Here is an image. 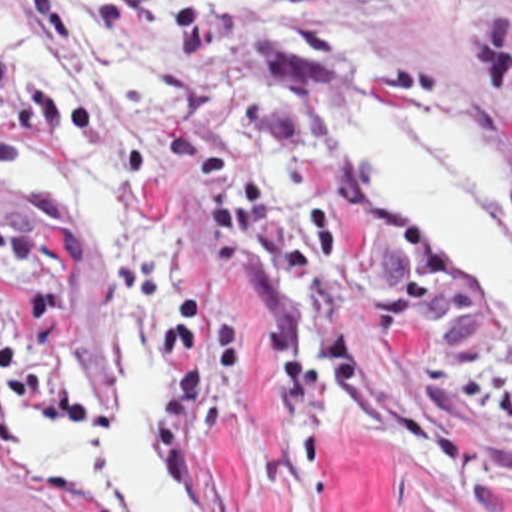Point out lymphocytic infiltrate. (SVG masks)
Segmentation results:
<instances>
[{
  "label": "lymphocytic infiltrate",
  "instance_id": "1",
  "mask_svg": "<svg viewBox=\"0 0 512 512\" xmlns=\"http://www.w3.org/2000/svg\"><path fill=\"white\" fill-rule=\"evenodd\" d=\"M85 157L107 177L167 169V147L73 99L19 85L0 61V173ZM101 294V256L81 197L41 175L0 206V444L17 452L15 406L61 444L97 436L119 410L89 382L79 314Z\"/></svg>",
  "mask_w": 512,
  "mask_h": 512
}]
</instances>
